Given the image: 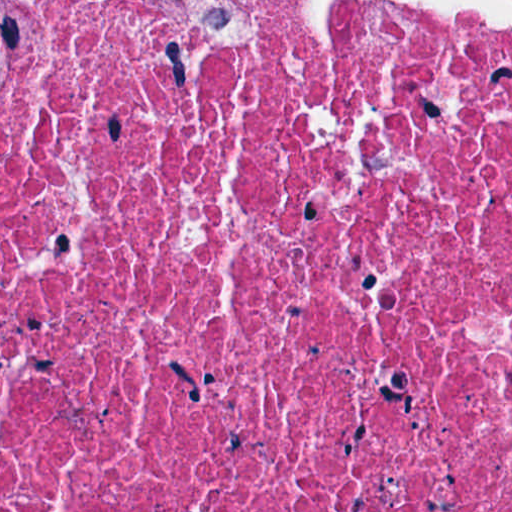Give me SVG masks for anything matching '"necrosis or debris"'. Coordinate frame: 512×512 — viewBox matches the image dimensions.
Here are the masks:
<instances>
[{"instance_id":"4bbe7bcc","label":"necrosis or debris","mask_w":512,"mask_h":512,"mask_svg":"<svg viewBox=\"0 0 512 512\" xmlns=\"http://www.w3.org/2000/svg\"><path fill=\"white\" fill-rule=\"evenodd\" d=\"M0 512H512V0H0Z\"/></svg>"}]
</instances>
